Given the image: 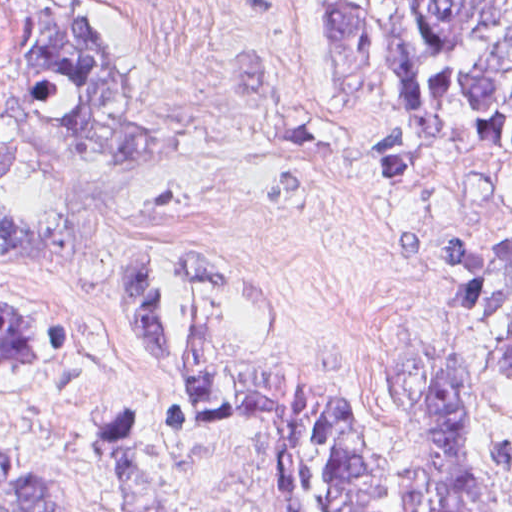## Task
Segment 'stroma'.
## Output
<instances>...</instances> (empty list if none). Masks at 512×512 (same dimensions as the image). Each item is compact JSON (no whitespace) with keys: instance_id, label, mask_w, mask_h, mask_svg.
<instances>
[{"instance_id":"obj_1","label":"stroma","mask_w":512,"mask_h":512,"mask_svg":"<svg viewBox=\"0 0 512 512\" xmlns=\"http://www.w3.org/2000/svg\"><path fill=\"white\" fill-rule=\"evenodd\" d=\"M105 13L155 119L135 238L163 259L177 327L186 255L218 248L268 290L285 371L349 391L385 424L394 412L377 360L388 343L462 351L472 360L469 413L512 439V375L483 366L489 346L512 334V313L457 319L446 297L462 286L460 268L406 262L401 248L406 223L431 246L479 225L512 232V163L472 147L436 178L365 176L350 162L355 141L404 131L387 55L345 90L321 51L319 0H112ZM0 292L29 297L64 331L51 376L0 386V443L38 467L53 512H125L92 441L103 412L121 406L143 411L155 456L183 483L185 512H287L268 408L206 410L181 434L162 427L184 390L145 336L129 287L0 252Z\"/></svg>"}]
</instances>
